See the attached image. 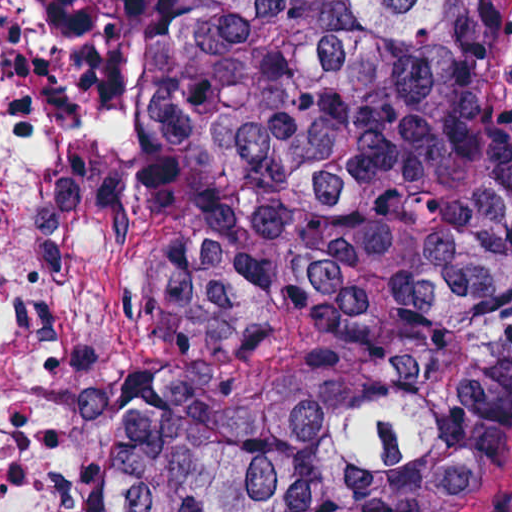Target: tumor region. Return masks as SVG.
<instances>
[{
	"label": "tumor region",
	"mask_w": 512,
	"mask_h": 512,
	"mask_svg": "<svg viewBox=\"0 0 512 512\" xmlns=\"http://www.w3.org/2000/svg\"><path fill=\"white\" fill-rule=\"evenodd\" d=\"M135 54L128 512H447L512 427V0H44Z\"/></svg>",
	"instance_id": "obj_1"
}]
</instances>
